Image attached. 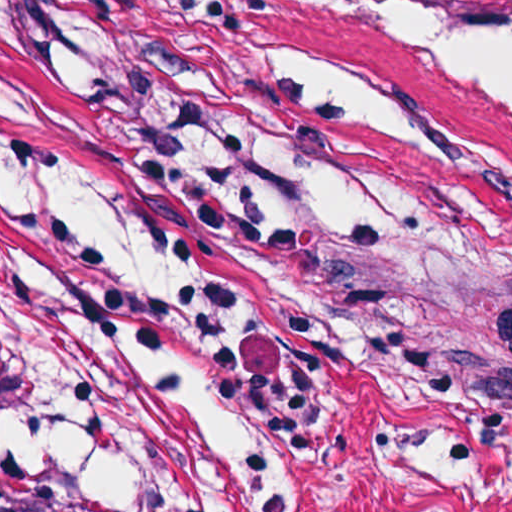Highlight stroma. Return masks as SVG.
Instances as JSON below:
<instances>
[{
  "instance_id": "obj_1",
  "label": "stroma",
  "mask_w": 512,
  "mask_h": 512,
  "mask_svg": "<svg viewBox=\"0 0 512 512\" xmlns=\"http://www.w3.org/2000/svg\"><path fill=\"white\" fill-rule=\"evenodd\" d=\"M371 6L0 0V50L77 125L188 291L274 458L146 484L12 445L103 512H512V123L371 43ZM316 262L311 284L290 256Z\"/></svg>"
}]
</instances>
